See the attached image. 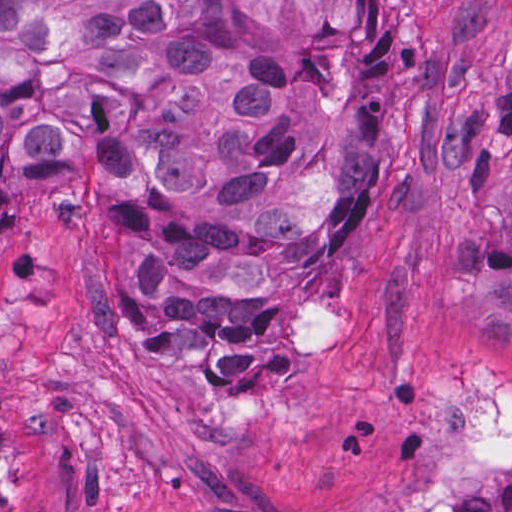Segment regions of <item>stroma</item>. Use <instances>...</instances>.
Returning <instances> with one entry per match:
<instances>
[{
  "label": "stroma",
  "instance_id": "1",
  "mask_svg": "<svg viewBox=\"0 0 512 512\" xmlns=\"http://www.w3.org/2000/svg\"><path fill=\"white\" fill-rule=\"evenodd\" d=\"M374 186L333 293L231 398L110 362L87 206L0 225V512H393L453 500L452 389L512 392V0H378Z\"/></svg>",
  "mask_w": 512,
  "mask_h": 512
}]
</instances>
